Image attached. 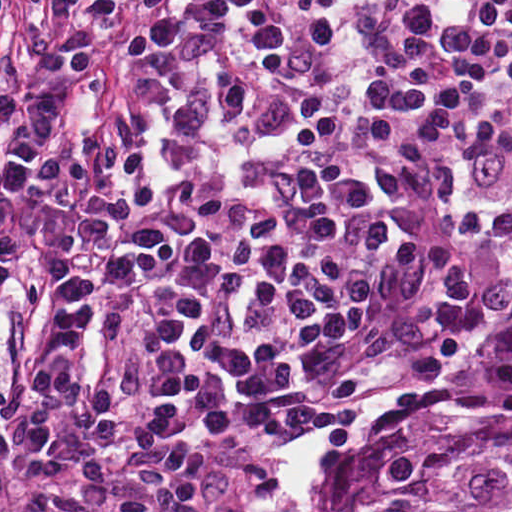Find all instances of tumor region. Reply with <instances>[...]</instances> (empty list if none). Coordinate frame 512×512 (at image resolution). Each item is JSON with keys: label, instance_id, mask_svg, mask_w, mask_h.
<instances>
[{"label": "tumor region", "instance_id": "obj_1", "mask_svg": "<svg viewBox=\"0 0 512 512\" xmlns=\"http://www.w3.org/2000/svg\"><path fill=\"white\" fill-rule=\"evenodd\" d=\"M331 512H512V287L460 370L351 429Z\"/></svg>", "mask_w": 512, "mask_h": 512}]
</instances>
